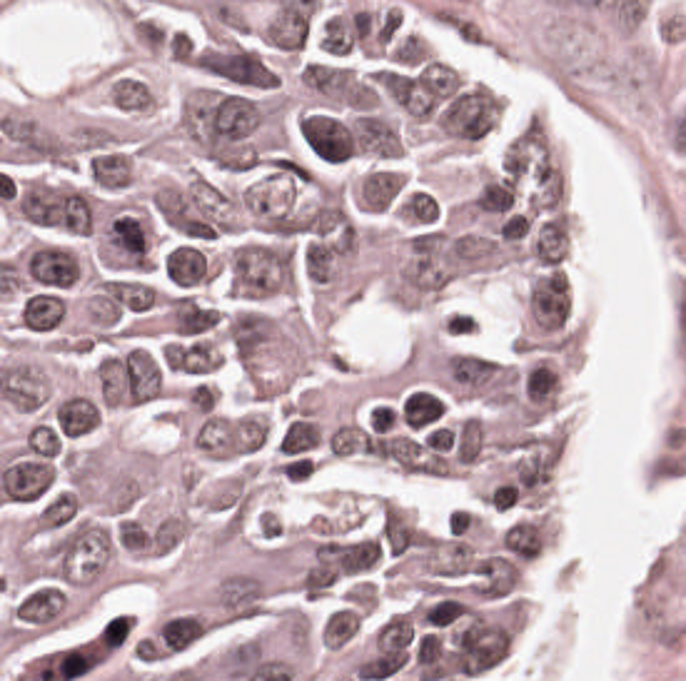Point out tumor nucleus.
<instances>
[{
  "label": "tumor nucleus",
  "mask_w": 686,
  "mask_h": 681,
  "mask_svg": "<svg viewBox=\"0 0 686 681\" xmlns=\"http://www.w3.org/2000/svg\"><path fill=\"white\" fill-rule=\"evenodd\" d=\"M292 282V249L285 241L244 234L224 246L221 287L241 300L274 294Z\"/></svg>",
  "instance_id": "obj_1"
},
{
  "label": "tumor nucleus",
  "mask_w": 686,
  "mask_h": 681,
  "mask_svg": "<svg viewBox=\"0 0 686 681\" xmlns=\"http://www.w3.org/2000/svg\"><path fill=\"white\" fill-rule=\"evenodd\" d=\"M225 197L207 180L191 179L154 192L147 205L179 235L212 237L222 227Z\"/></svg>",
  "instance_id": "obj_2"
},
{
  "label": "tumor nucleus",
  "mask_w": 686,
  "mask_h": 681,
  "mask_svg": "<svg viewBox=\"0 0 686 681\" xmlns=\"http://www.w3.org/2000/svg\"><path fill=\"white\" fill-rule=\"evenodd\" d=\"M14 205L27 222L64 230H90L87 196L68 184L29 179Z\"/></svg>",
  "instance_id": "obj_3"
}]
</instances>
